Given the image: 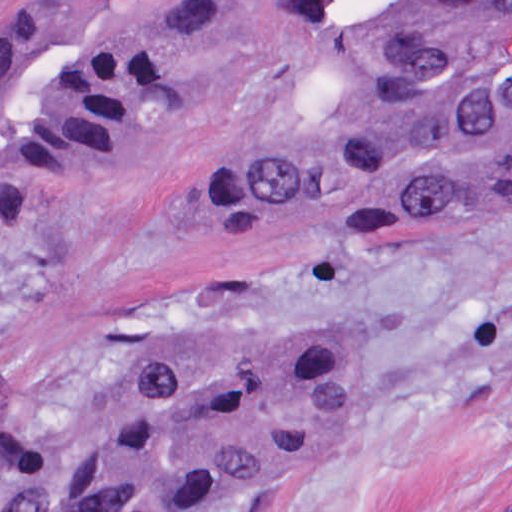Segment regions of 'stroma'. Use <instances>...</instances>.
Masks as SVG:
<instances>
[{"label":"stroma","instance_id":"1","mask_svg":"<svg viewBox=\"0 0 512 512\" xmlns=\"http://www.w3.org/2000/svg\"><path fill=\"white\" fill-rule=\"evenodd\" d=\"M37 0H0V37ZM205 69L130 166L61 181L27 222L0 186V430L154 358L320 338L350 360L320 458L216 512H512V202L397 239H313L205 186L326 105L284 77L267 0H225ZM49 486L0 468V512Z\"/></svg>","mask_w":512,"mask_h":512}]
</instances>
